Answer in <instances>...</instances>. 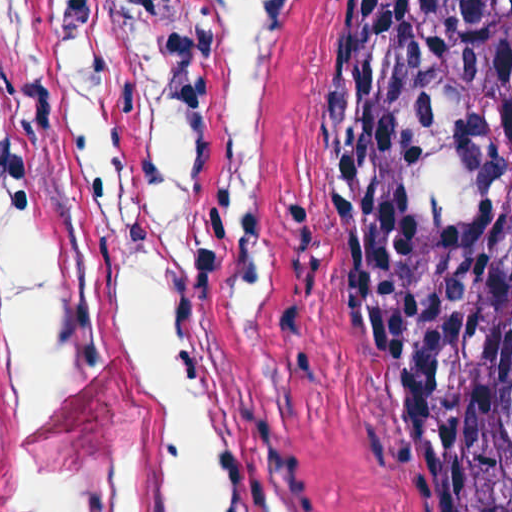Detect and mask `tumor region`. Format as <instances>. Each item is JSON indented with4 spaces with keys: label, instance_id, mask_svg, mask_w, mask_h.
I'll return each instance as SVG.
<instances>
[{
    "label": "tumor region",
    "instance_id": "e687c5a6",
    "mask_svg": "<svg viewBox=\"0 0 512 512\" xmlns=\"http://www.w3.org/2000/svg\"><path fill=\"white\" fill-rule=\"evenodd\" d=\"M298 265L404 380L457 512H512V0H335Z\"/></svg>",
    "mask_w": 512,
    "mask_h": 512
}]
</instances>
